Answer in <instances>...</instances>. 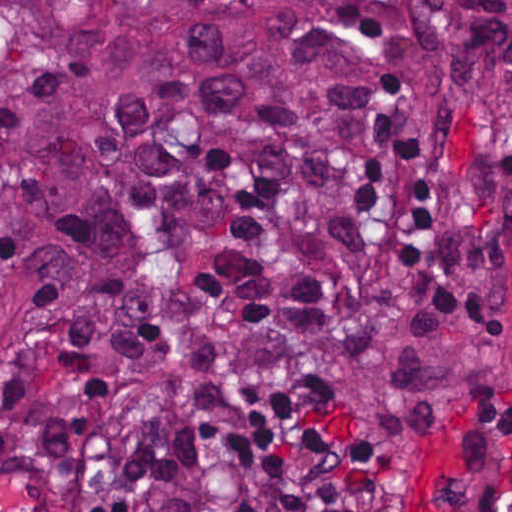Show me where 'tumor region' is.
<instances>
[{
    "instance_id": "1",
    "label": "tumor region",
    "mask_w": 512,
    "mask_h": 512,
    "mask_svg": "<svg viewBox=\"0 0 512 512\" xmlns=\"http://www.w3.org/2000/svg\"><path fill=\"white\" fill-rule=\"evenodd\" d=\"M423 43L512 120V0H0V359L91 234L241 158L325 166Z\"/></svg>"
}]
</instances>
